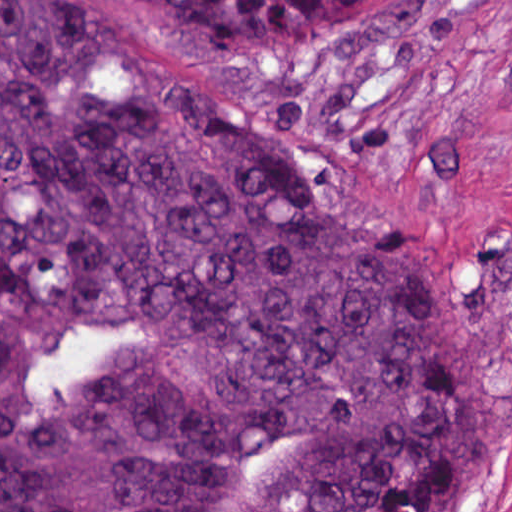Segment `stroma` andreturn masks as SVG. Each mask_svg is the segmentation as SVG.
I'll return each mask as SVG.
<instances>
[{
  "label": "stroma",
  "instance_id": "obj_1",
  "mask_svg": "<svg viewBox=\"0 0 512 512\" xmlns=\"http://www.w3.org/2000/svg\"><path fill=\"white\" fill-rule=\"evenodd\" d=\"M125 1L279 111L463 269L478 294L472 512H512V0H401L334 49L196 37Z\"/></svg>",
  "mask_w": 512,
  "mask_h": 512
}]
</instances>
